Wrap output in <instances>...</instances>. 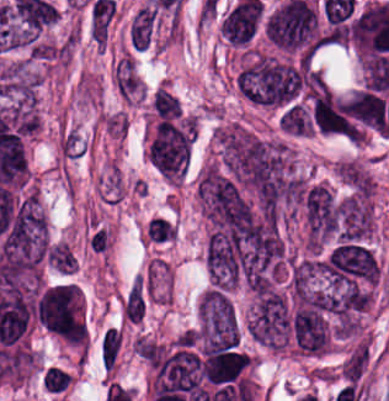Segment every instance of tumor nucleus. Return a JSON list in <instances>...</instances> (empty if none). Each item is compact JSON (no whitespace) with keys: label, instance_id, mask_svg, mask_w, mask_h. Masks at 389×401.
I'll return each mask as SVG.
<instances>
[{"label":"tumor nucleus","instance_id":"tumor-nucleus-2","mask_svg":"<svg viewBox=\"0 0 389 401\" xmlns=\"http://www.w3.org/2000/svg\"><path fill=\"white\" fill-rule=\"evenodd\" d=\"M38 321L66 337H82V295L76 282L51 284L40 290L34 302Z\"/></svg>","mask_w":389,"mask_h":401},{"label":"tumor nucleus","instance_id":"tumor-nucleus-1","mask_svg":"<svg viewBox=\"0 0 389 401\" xmlns=\"http://www.w3.org/2000/svg\"><path fill=\"white\" fill-rule=\"evenodd\" d=\"M196 333L200 347L237 348L239 316L229 293L222 287L209 285L200 295Z\"/></svg>","mask_w":389,"mask_h":401},{"label":"tumor nucleus","instance_id":"tumor-nucleus-3","mask_svg":"<svg viewBox=\"0 0 389 401\" xmlns=\"http://www.w3.org/2000/svg\"><path fill=\"white\" fill-rule=\"evenodd\" d=\"M153 401L192 390L198 386L199 359L192 350L176 347L149 361Z\"/></svg>","mask_w":389,"mask_h":401}]
</instances>
